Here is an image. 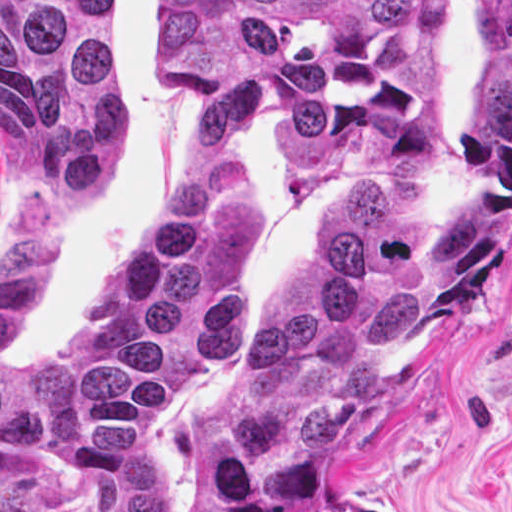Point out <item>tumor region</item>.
Masks as SVG:
<instances>
[{"label": "tumor region", "instance_id": "1", "mask_svg": "<svg viewBox=\"0 0 512 512\" xmlns=\"http://www.w3.org/2000/svg\"><path fill=\"white\" fill-rule=\"evenodd\" d=\"M451 0H167V76L208 133L256 109L320 181L431 145ZM121 0H0V147L37 195L78 203L121 154L111 45ZM512 239V0H483L460 193L383 177L301 263L200 436L188 512H302L334 486L354 422L422 368ZM53 263L30 202L0 253V512H43L51 454L97 512H184L156 463L159 409L247 327V181L205 142L175 203L37 367L11 363ZM331 512H376L349 500Z\"/></svg>", "mask_w": 512, "mask_h": 512}]
</instances>
